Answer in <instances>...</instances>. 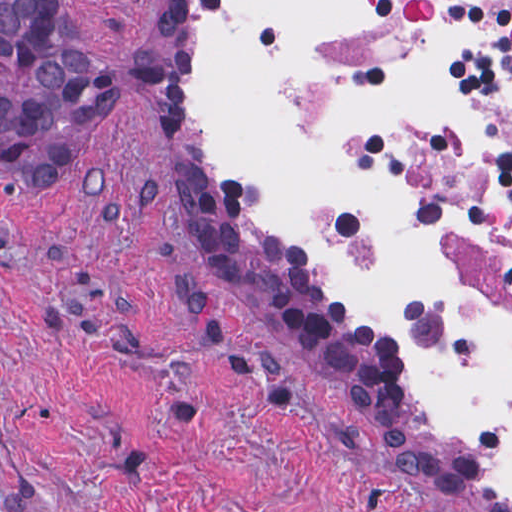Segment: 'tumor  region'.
<instances>
[{
  "label": "tumor region",
  "instance_id": "e687c5a6",
  "mask_svg": "<svg viewBox=\"0 0 512 512\" xmlns=\"http://www.w3.org/2000/svg\"><path fill=\"white\" fill-rule=\"evenodd\" d=\"M0 69L34 93L0 88V167L47 184L120 96L159 80L155 55L118 61L85 47L58 0H0Z\"/></svg>",
  "mask_w": 512,
  "mask_h": 512
}]
</instances>
